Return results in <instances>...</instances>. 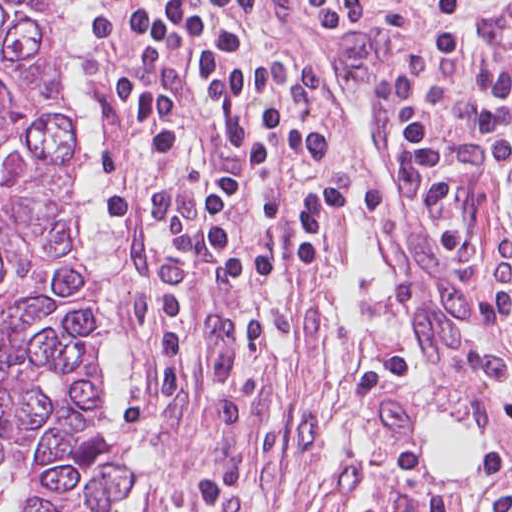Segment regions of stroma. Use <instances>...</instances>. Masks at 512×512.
Returning <instances> with one entry per match:
<instances>
[{
	"instance_id": "35a3bbf8",
	"label": "stroma",
	"mask_w": 512,
	"mask_h": 512,
	"mask_svg": "<svg viewBox=\"0 0 512 512\" xmlns=\"http://www.w3.org/2000/svg\"><path fill=\"white\" fill-rule=\"evenodd\" d=\"M480 1L512 0H458L457 7ZM74 12L86 93L92 245L83 244L82 116L72 80L78 249L68 254L91 270L106 319L101 396L108 447L131 480L127 512H512V459L495 457L454 474L428 472L415 456L404 418L388 401L367 410L369 451L363 459L334 465L321 438L326 408L335 381L364 356L317 342L280 350L262 337L258 314L264 299L345 276L355 219L366 215L388 239L434 383L473 406L493 432L498 429L434 316L419 271L351 134L350 215L328 266L303 281L251 282V309L234 298L210 300L186 329L176 393L166 404L149 403V323L158 301L194 263L164 245L148 248L107 236L101 224L96 229L95 121L76 0ZM285 12L292 20L285 8L262 16L256 57L302 54L292 44ZM385 42L375 41L376 47ZM501 351L512 366V328ZM8 480L16 491V512H24V489Z\"/></svg>"
}]
</instances>
